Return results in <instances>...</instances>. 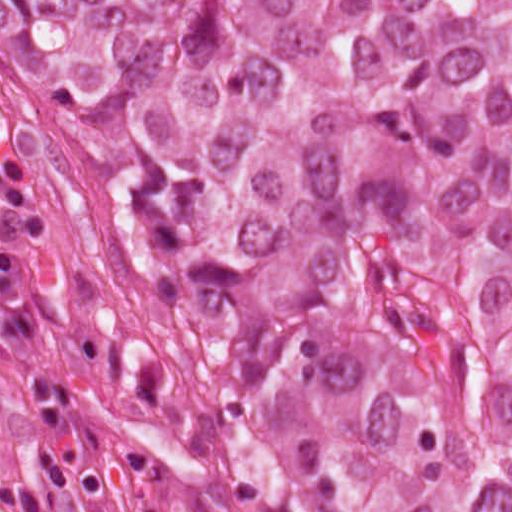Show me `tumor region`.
Wrapping results in <instances>:
<instances>
[{
  "mask_svg": "<svg viewBox=\"0 0 512 512\" xmlns=\"http://www.w3.org/2000/svg\"><path fill=\"white\" fill-rule=\"evenodd\" d=\"M0 252L170 512H512V0H0Z\"/></svg>",
  "mask_w": 512,
  "mask_h": 512,
  "instance_id": "obj_1",
  "label": "tumor region"
}]
</instances>
